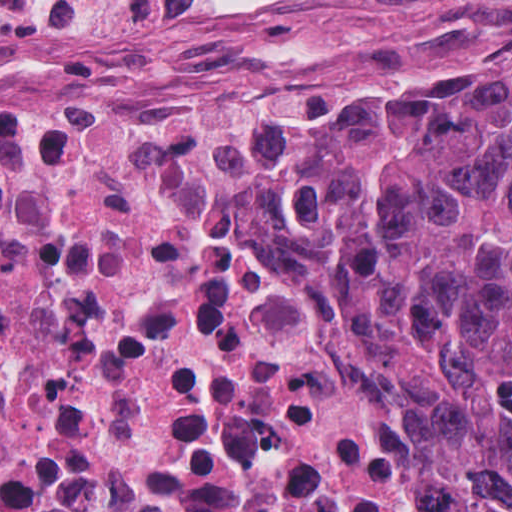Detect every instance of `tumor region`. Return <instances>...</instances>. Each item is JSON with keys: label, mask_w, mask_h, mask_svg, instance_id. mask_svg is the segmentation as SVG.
<instances>
[{"label": "tumor region", "mask_w": 512, "mask_h": 512, "mask_svg": "<svg viewBox=\"0 0 512 512\" xmlns=\"http://www.w3.org/2000/svg\"><path fill=\"white\" fill-rule=\"evenodd\" d=\"M458 512H512V64L375 75L271 119Z\"/></svg>", "instance_id": "obj_1"}]
</instances>
